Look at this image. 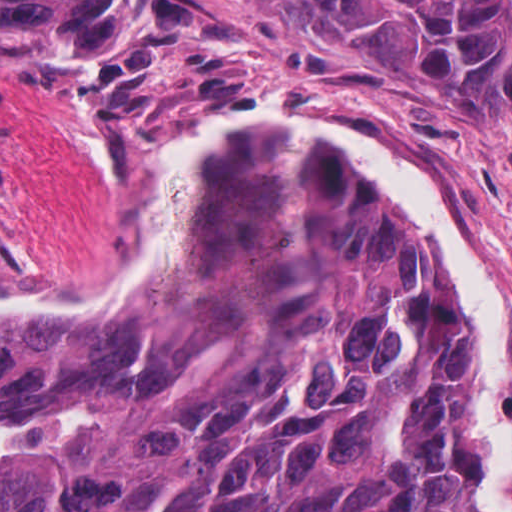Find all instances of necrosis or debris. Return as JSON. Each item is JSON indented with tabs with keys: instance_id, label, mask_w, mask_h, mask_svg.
Here are the masks:
<instances>
[{
	"instance_id": "4bbe7bcc",
	"label": "necrosis or debris",
	"mask_w": 512,
	"mask_h": 512,
	"mask_svg": "<svg viewBox=\"0 0 512 512\" xmlns=\"http://www.w3.org/2000/svg\"><path fill=\"white\" fill-rule=\"evenodd\" d=\"M0 197H1V154H0ZM16 260V255L0 239V274Z\"/></svg>"
}]
</instances>
